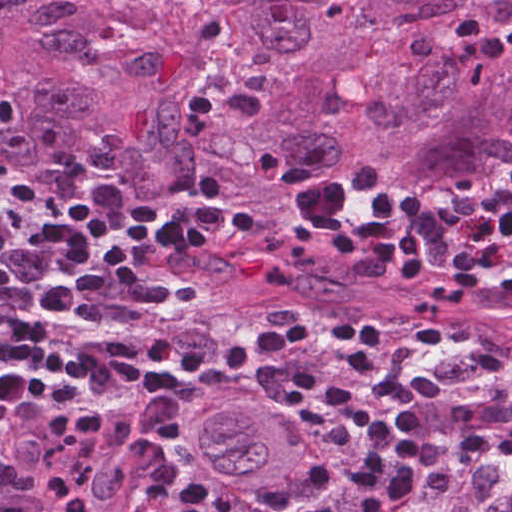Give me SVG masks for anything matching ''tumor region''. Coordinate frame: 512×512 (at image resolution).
Returning a JSON list of instances; mask_svg holds the SVG:
<instances>
[{
    "label": "tumor region",
    "mask_w": 512,
    "mask_h": 512,
    "mask_svg": "<svg viewBox=\"0 0 512 512\" xmlns=\"http://www.w3.org/2000/svg\"><path fill=\"white\" fill-rule=\"evenodd\" d=\"M283 71L246 126L187 135L199 44L166 0H0V77L162 223L192 220L202 182L256 221L200 256L249 301L365 317L512 369V299H437L472 248L437 207L512 167V0H216ZM424 192L431 272L335 255L384 189ZM476 249V248H474ZM494 284L512 280V240Z\"/></svg>",
    "instance_id": "e687c5a6"
}]
</instances>
